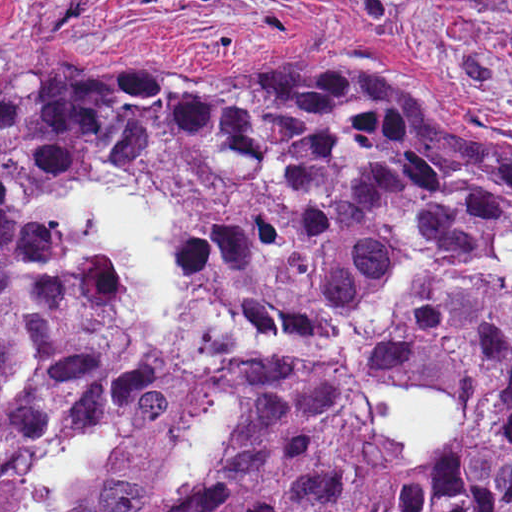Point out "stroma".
Here are the masks:
<instances>
[{"label":"stroma","mask_w":512,"mask_h":512,"mask_svg":"<svg viewBox=\"0 0 512 512\" xmlns=\"http://www.w3.org/2000/svg\"><path fill=\"white\" fill-rule=\"evenodd\" d=\"M347 60L382 66L414 102L462 115L512 161V0H0V79L285 73ZM370 382L474 402L432 374L377 369ZM364 406L373 419L390 409Z\"/></svg>","instance_id":"35a3bbf8"}]
</instances>
